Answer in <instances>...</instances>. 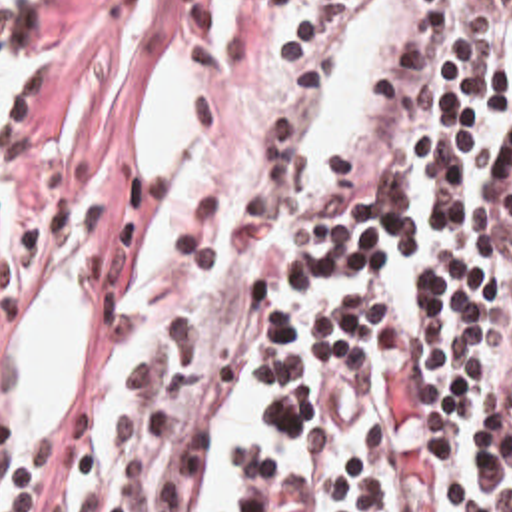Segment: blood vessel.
Instances as JSON below:
<instances>
[{"label":"blood vessel","instance_id":"obj_1","mask_svg":"<svg viewBox=\"0 0 512 512\" xmlns=\"http://www.w3.org/2000/svg\"><path fill=\"white\" fill-rule=\"evenodd\" d=\"M439 0H347L289 113L277 197L299 227H335L387 185L431 53Z\"/></svg>","mask_w":512,"mask_h":512}]
</instances>
